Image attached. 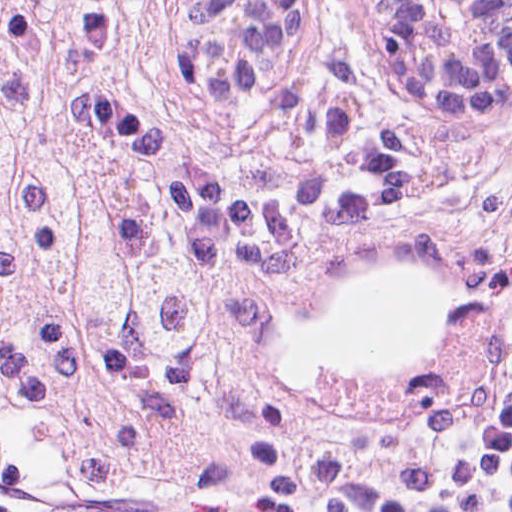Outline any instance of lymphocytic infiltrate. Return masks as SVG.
Here are the masks:
<instances>
[{
	"instance_id": "lymphocytic-infiltrate-1",
	"label": "lymphocytic infiltrate",
	"mask_w": 512,
	"mask_h": 512,
	"mask_svg": "<svg viewBox=\"0 0 512 512\" xmlns=\"http://www.w3.org/2000/svg\"><path fill=\"white\" fill-rule=\"evenodd\" d=\"M488 140L461 159V183L481 224L512 241V197L487 173ZM512 314V306L507 316ZM384 512H449L423 478L408 447L395 458L385 492Z\"/></svg>"
}]
</instances>
